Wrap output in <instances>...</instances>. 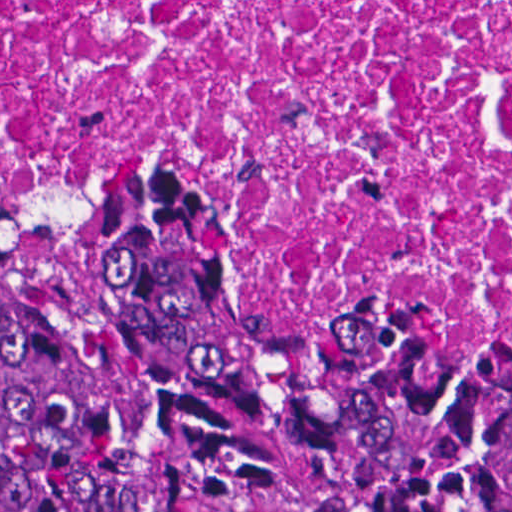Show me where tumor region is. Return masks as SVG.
<instances>
[{"label":"tumor region","mask_w":512,"mask_h":512,"mask_svg":"<svg viewBox=\"0 0 512 512\" xmlns=\"http://www.w3.org/2000/svg\"><path fill=\"white\" fill-rule=\"evenodd\" d=\"M1 479L50 512H512V361L274 312L194 211L95 204L1 264Z\"/></svg>","instance_id":"obj_1"}]
</instances>
